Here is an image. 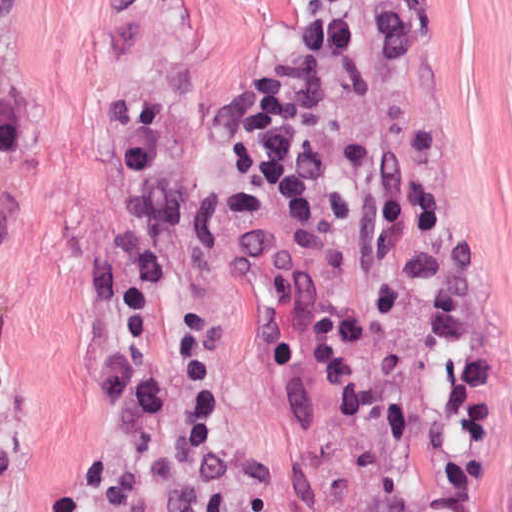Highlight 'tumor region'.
I'll use <instances>...</instances> for the list:
<instances>
[{
  "label": "tumor region",
  "mask_w": 512,
  "mask_h": 512,
  "mask_svg": "<svg viewBox=\"0 0 512 512\" xmlns=\"http://www.w3.org/2000/svg\"><path fill=\"white\" fill-rule=\"evenodd\" d=\"M262 216L278 292L392 512H512V328L398 74L277 0Z\"/></svg>",
  "instance_id": "tumor-region-1"
}]
</instances>
